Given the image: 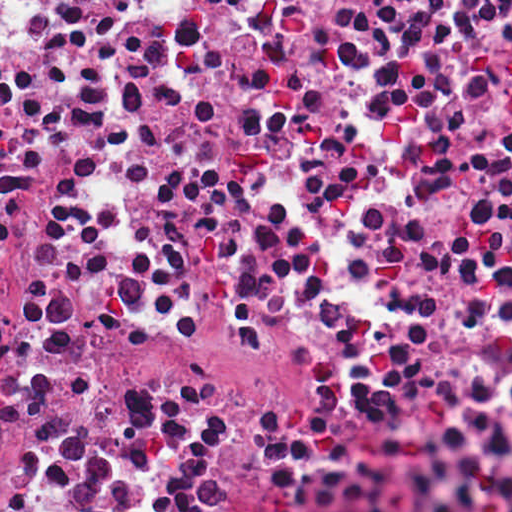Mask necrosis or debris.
<instances>
[{"mask_svg":"<svg viewBox=\"0 0 512 512\" xmlns=\"http://www.w3.org/2000/svg\"><path fill=\"white\" fill-rule=\"evenodd\" d=\"M512 306V0H0V512Z\"/></svg>","mask_w":512,"mask_h":512,"instance_id":"1","label":"necrosis or debris"}]
</instances>
